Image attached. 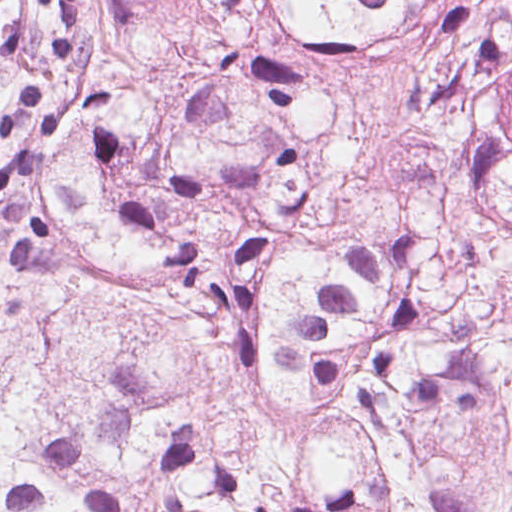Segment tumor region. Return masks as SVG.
Segmentation results:
<instances>
[{"label": "tumor region", "mask_w": 512, "mask_h": 512, "mask_svg": "<svg viewBox=\"0 0 512 512\" xmlns=\"http://www.w3.org/2000/svg\"><path fill=\"white\" fill-rule=\"evenodd\" d=\"M0 512H512V0H0Z\"/></svg>", "instance_id": "tumor-region-1"}]
</instances>
